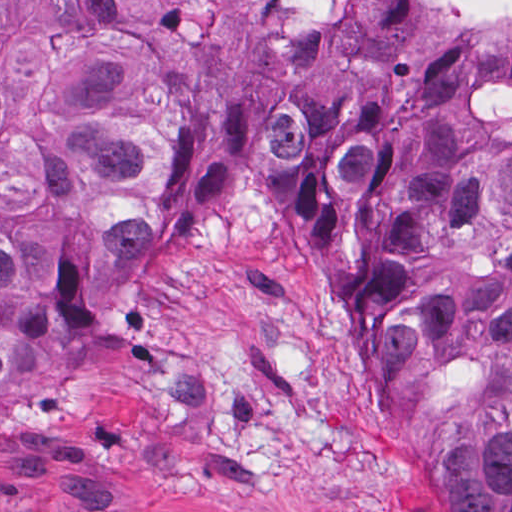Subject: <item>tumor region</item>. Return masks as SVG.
Returning a JSON list of instances; mask_svg holds the SVG:
<instances>
[{
  "instance_id": "obj_1",
  "label": "tumor region",
  "mask_w": 512,
  "mask_h": 512,
  "mask_svg": "<svg viewBox=\"0 0 512 512\" xmlns=\"http://www.w3.org/2000/svg\"><path fill=\"white\" fill-rule=\"evenodd\" d=\"M228 194L348 387L512 512V50L433 0H0V387L62 293Z\"/></svg>"
}]
</instances>
